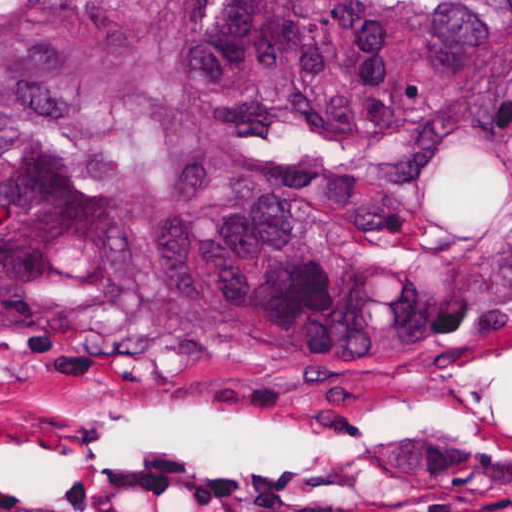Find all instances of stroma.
<instances>
[{"instance_id": "obj_1", "label": "stroma", "mask_w": 512, "mask_h": 512, "mask_svg": "<svg viewBox=\"0 0 512 512\" xmlns=\"http://www.w3.org/2000/svg\"><path fill=\"white\" fill-rule=\"evenodd\" d=\"M0 512H512V308L400 373L0 340Z\"/></svg>"}]
</instances>
